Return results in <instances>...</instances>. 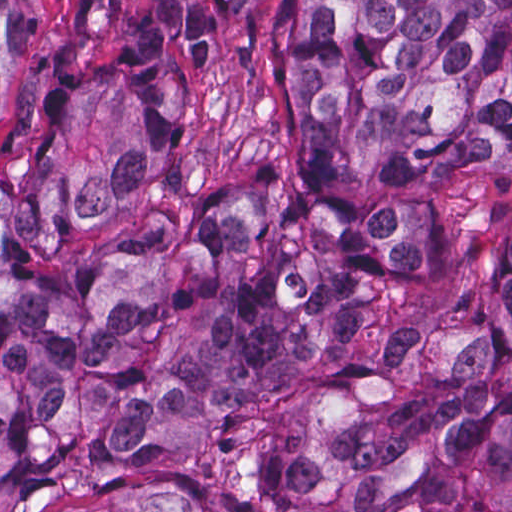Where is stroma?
<instances>
[{
  "instance_id": "stroma-1",
  "label": "stroma",
  "mask_w": 512,
  "mask_h": 512,
  "mask_svg": "<svg viewBox=\"0 0 512 512\" xmlns=\"http://www.w3.org/2000/svg\"><path fill=\"white\" fill-rule=\"evenodd\" d=\"M10 58L0 99V169L23 160L61 113L137 52L143 0H4Z\"/></svg>"
}]
</instances>
